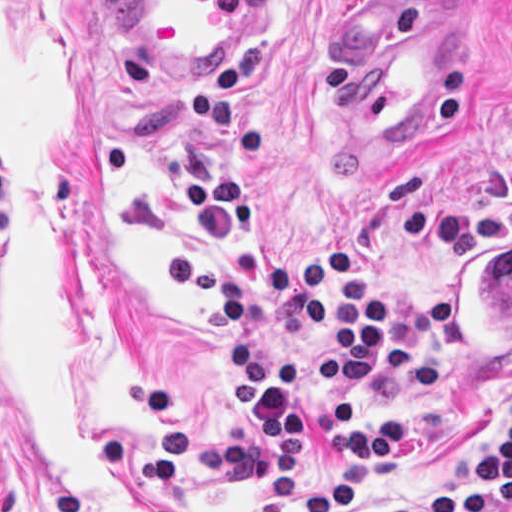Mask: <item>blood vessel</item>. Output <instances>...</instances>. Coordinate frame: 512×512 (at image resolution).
I'll return each mask as SVG.
<instances>
[{
  "label": "blood vessel",
  "mask_w": 512,
  "mask_h": 512,
  "mask_svg": "<svg viewBox=\"0 0 512 512\" xmlns=\"http://www.w3.org/2000/svg\"><path fill=\"white\" fill-rule=\"evenodd\" d=\"M280 1L129 0V14L163 66L217 72L267 28ZM457 2L415 4L348 36L341 107L356 138L398 148L433 114L463 53Z\"/></svg>",
  "instance_id": "obj_1"
}]
</instances>
